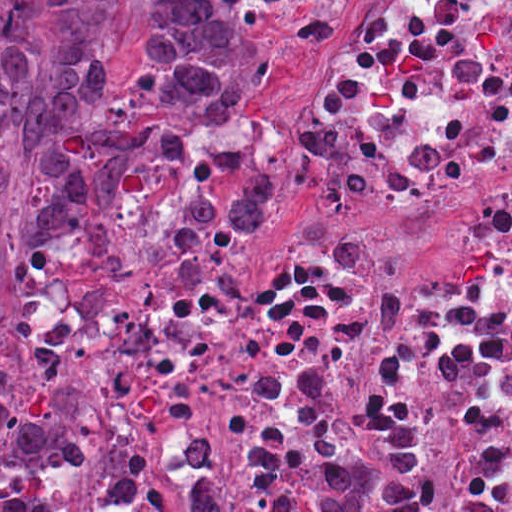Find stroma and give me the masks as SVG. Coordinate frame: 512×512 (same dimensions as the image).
Wrapping results in <instances>:
<instances>
[{"label":"stroma","mask_w":512,"mask_h":512,"mask_svg":"<svg viewBox=\"0 0 512 512\" xmlns=\"http://www.w3.org/2000/svg\"><path fill=\"white\" fill-rule=\"evenodd\" d=\"M300 1L263 23L272 87L253 125L272 167V200L247 230L208 245L162 237L127 266L96 263L67 237L33 243L17 229L28 168L0 146V356L10 358L24 403L78 438V512L103 511L136 361L187 326L164 295L171 274L275 258L313 216V196L292 188L286 151L330 41L361 0Z\"/></svg>","instance_id":"stroma-1"}]
</instances>
